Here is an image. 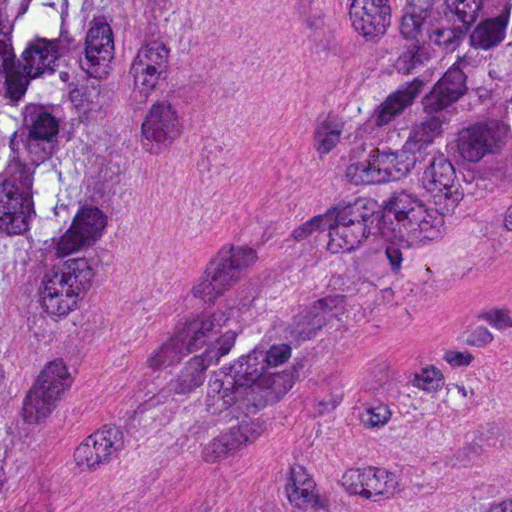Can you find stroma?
I'll use <instances>...</instances> for the list:
<instances>
[{
	"instance_id": "obj_1",
	"label": "stroma",
	"mask_w": 512,
	"mask_h": 512,
	"mask_svg": "<svg viewBox=\"0 0 512 512\" xmlns=\"http://www.w3.org/2000/svg\"><path fill=\"white\" fill-rule=\"evenodd\" d=\"M147 1L110 300L0 339V512H512V219L420 261L253 403L175 399L208 293L387 67L389 10Z\"/></svg>"
}]
</instances>
